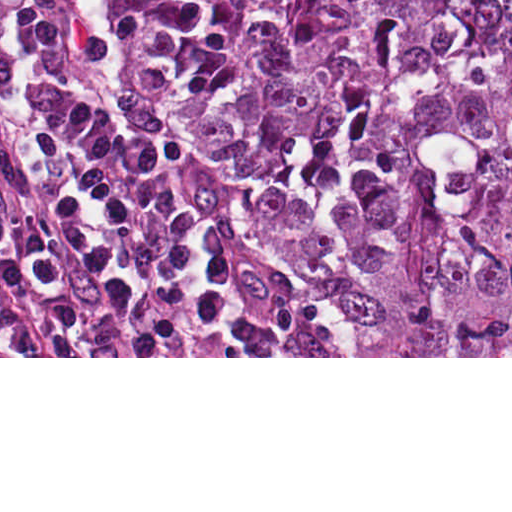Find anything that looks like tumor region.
I'll use <instances>...</instances> for the list:
<instances>
[{"instance_id": "e687c5a6", "label": "tumor region", "mask_w": 512, "mask_h": 512, "mask_svg": "<svg viewBox=\"0 0 512 512\" xmlns=\"http://www.w3.org/2000/svg\"><path fill=\"white\" fill-rule=\"evenodd\" d=\"M110 2L115 94L241 174L348 356H512V0Z\"/></svg>"}]
</instances>
